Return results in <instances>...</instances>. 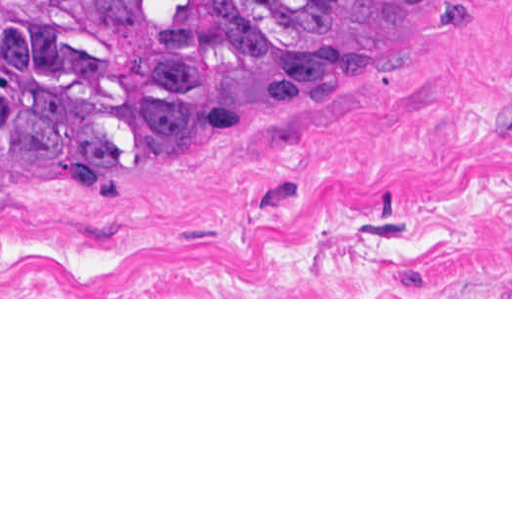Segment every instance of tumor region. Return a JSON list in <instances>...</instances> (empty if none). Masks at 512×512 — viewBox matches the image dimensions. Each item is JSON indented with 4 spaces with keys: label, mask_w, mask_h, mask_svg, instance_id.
<instances>
[{
    "label": "tumor region",
    "mask_w": 512,
    "mask_h": 512,
    "mask_svg": "<svg viewBox=\"0 0 512 512\" xmlns=\"http://www.w3.org/2000/svg\"><path fill=\"white\" fill-rule=\"evenodd\" d=\"M447 0H0V161L142 168L318 75L390 53Z\"/></svg>",
    "instance_id": "tumor-region-1"
}]
</instances>
